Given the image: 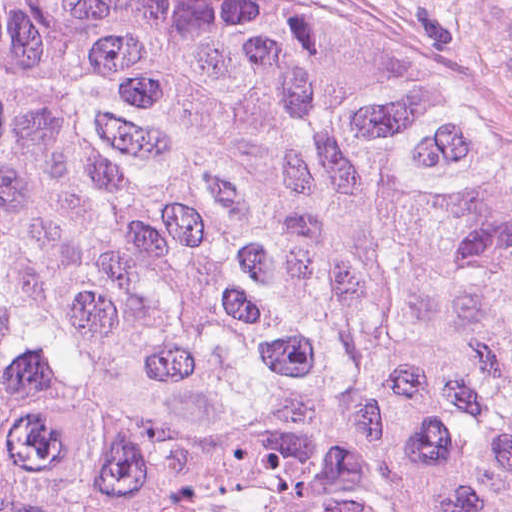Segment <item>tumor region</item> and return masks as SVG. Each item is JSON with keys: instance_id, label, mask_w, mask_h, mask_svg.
Masks as SVG:
<instances>
[{"instance_id": "obj_1", "label": "tumor region", "mask_w": 512, "mask_h": 512, "mask_svg": "<svg viewBox=\"0 0 512 512\" xmlns=\"http://www.w3.org/2000/svg\"><path fill=\"white\" fill-rule=\"evenodd\" d=\"M0 512H512V143L359 39L0 0Z\"/></svg>"}]
</instances>
